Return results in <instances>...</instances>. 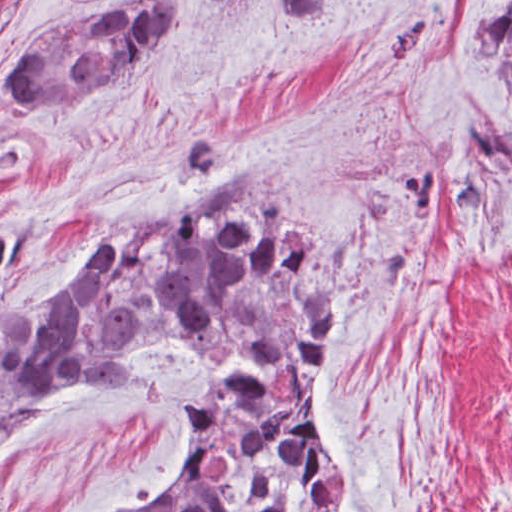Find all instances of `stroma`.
<instances>
[{
	"instance_id": "stroma-1",
	"label": "stroma",
	"mask_w": 512,
	"mask_h": 512,
	"mask_svg": "<svg viewBox=\"0 0 512 512\" xmlns=\"http://www.w3.org/2000/svg\"><path fill=\"white\" fill-rule=\"evenodd\" d=\"M112 1L0 0V328L111 228L258 176L347 246L319 404L345 512H512V106L469 46L512 0H184L93 97L16 102L27 44ZM207 380L189 343L86 373L8 428L0 512L159 505Z\"/></svg>"
}]
</instances>
